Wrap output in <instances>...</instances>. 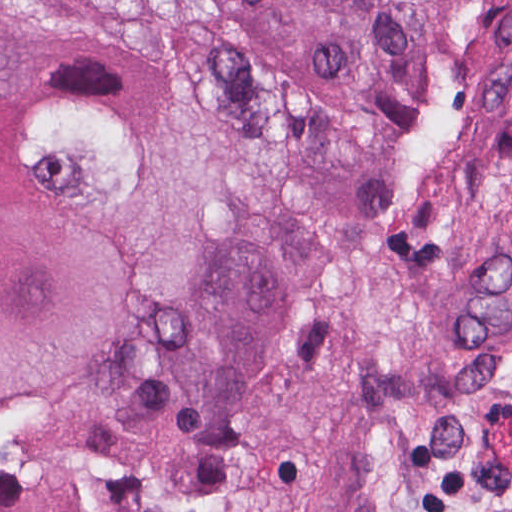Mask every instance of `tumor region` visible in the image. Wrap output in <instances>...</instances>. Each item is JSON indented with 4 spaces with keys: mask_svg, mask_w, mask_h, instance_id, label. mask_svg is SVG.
Instances as JSON below:
<instances>
[{
    "mask_svg": "<svg viewBox=\"0 0 512 512\" xmlns=\"http://www.w3.org/2000/svg\"><path fill=\"white\" fill-rule=\"evenodd\" d=\"M468 1L0 0V512H203Z\"/></svg>",
    "mask_w": 512,
    "mask_h": 512,
    "instance_id": "obj_1",
    "label": "tumor region"
}]
</instances>
